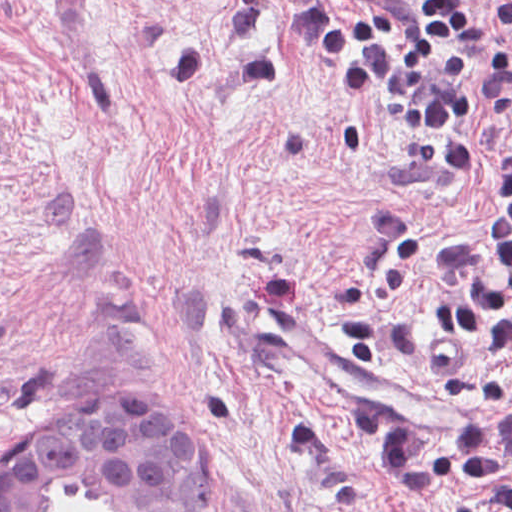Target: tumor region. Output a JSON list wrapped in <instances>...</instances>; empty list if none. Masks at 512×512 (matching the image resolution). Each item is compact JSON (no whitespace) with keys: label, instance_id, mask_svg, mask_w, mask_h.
I'll list each match as a JSON object with an SVG mask.
<instances>
[{"label":"tumor region","instance_id":"obj_1","mask_svg":"<svg viewBox=\"0 0 512 512\" xmlns=\"http://www.w3.org/2000/svg\"><path fill=\"white\" fill-rule=\"evenodd\" d=\"M26 439L0 470V512H45L48 496L69 485H92L103 512H213L204 452L157 400H90L21 452Z\"/></svg>","mask_w":512,"mask_h":512}]
</instances>
